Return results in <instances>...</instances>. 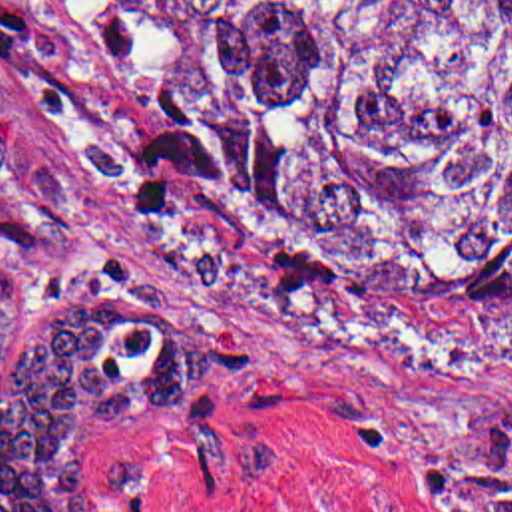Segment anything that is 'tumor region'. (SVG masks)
<instances>
[{"mask_svg": "<svg viewBox=\"0 0 512 512\" xmlns=\"http://www.w3.org/2000/svg\"><path fill=\"white\" fill-rule=\"evenodd\" d=\"M183 79L181 155L294 247L382 276H464L512 380V0H135ZM169 292L71 274L0 382V512H99L77 458L215 372ZM14 263L0 251V370ZM448 512H512V418L472 428Z\"/></svg>", "mask_w": 512, "mask_h": 512, "instance_id": "obj_1", "label": "tumor region"}]
</instances>
